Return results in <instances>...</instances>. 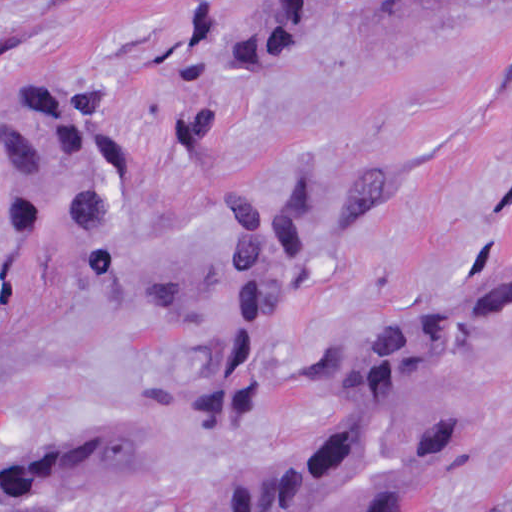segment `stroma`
Wrapping results in <instances>:
<instances>
[{
	"instance_id": "35a3bbf8",
	"label": "stroma",
	"mask_w": 512,
	"mask_h": 512,
	"mask_svg": "<svg viewBox=\"0 0 512 512\" xmlns=\"http://www.w3.org/2000/svg\"><path fill=\"white\" fill-rule=\"evenodd\" d=\"M248 2L0 0V213L20 127L86 78L126 148L129 221L157 249L190 242L278 160L394 177L368 236L268 326L250 423H205L190 347L149 314L71 318L26 345L0 370L1 455L130 423L165 437L173 461L138 492L27 494L0 499V512H193L317 435L328 396L301 391L331 350L494 262L512 200V0H439L309 63L220 76L197 39ZM473 364L483 434L437 512H512V308L481 329Z\"/></svg>"
}]
</instances>
